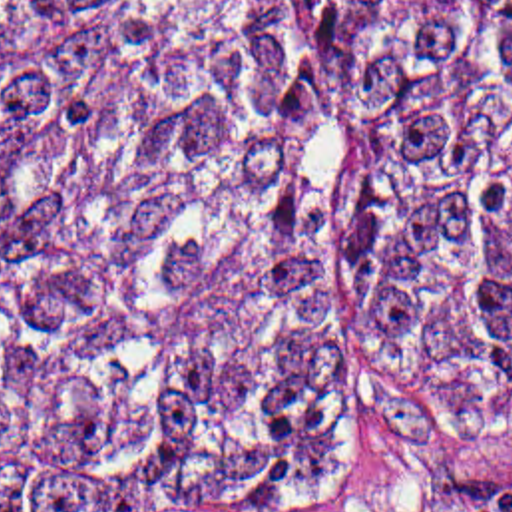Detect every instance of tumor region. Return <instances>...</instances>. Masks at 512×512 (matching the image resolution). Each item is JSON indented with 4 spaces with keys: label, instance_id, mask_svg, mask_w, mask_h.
<instances>
[{
    "label": "tumor region",
    "instance_id": "tumor-region-1",
    "mask_svg": "<svg viewBox=\"0 0 512 512\" xmlns=\"http://www.w3.org/2000/svg\"><path fill=\"white\" fill-rule=\"evenodd\" d=\"M411 396H512V0H0V512H325Z\"/></svg>",
    "mask_w": 512,
    "mask_h": 512
}]
</instances>
